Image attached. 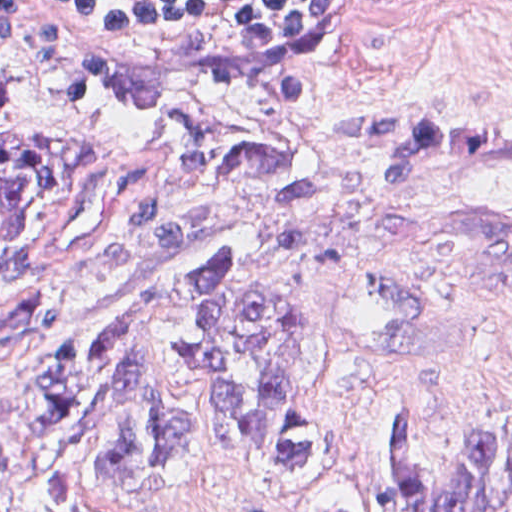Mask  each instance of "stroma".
<instances>
[{"label":"stroma","instance_id":"stroma-1","mask_svg":"<svg viewBox=\"0 0 512 512\" xmlns=\"http://www.w3.org/2000/svg\"><path fill=\"white\" fill-rule=\"evenodd\" d=\"M52 1H337L331 16L261 71L170 63L81 38ZM0 79L51 128L105 150L87 204L50 227L23 282L55 274L107 191L148 142L185 115L267 132L301 151L325 202L466 217L512 210V158H472L441 184H394L343 136L349 107L512 103V0H0ZM354 235V259L326 272L327 340L318 405L340 470L318 494L270 487L216 463L159 507L113 512H319L350 493L388 512L390 412L408 406L437 431L434 464L476 450L481 422L512 428V301L444 279Z\"/></svg>","mask_w":512,"mask_h":512}]
</instances>
